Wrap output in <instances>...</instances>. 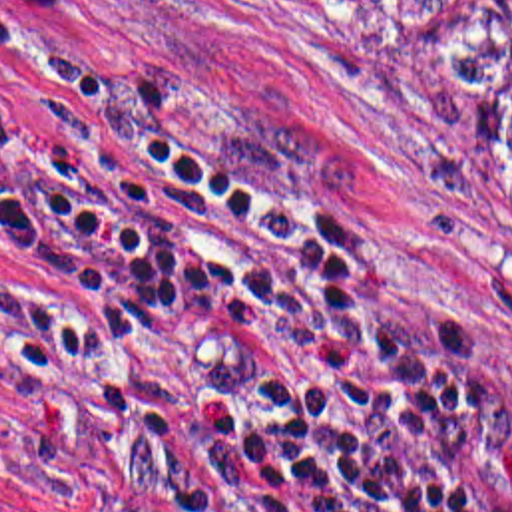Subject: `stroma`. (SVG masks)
Returning <instances> with one entry per match:
<instances>
[{
  "mask_svg": "<svg viewBox=\"0 0 512 512\" xmlns=\"http://www.w3.org/2000/svg\"><path fill=\"white\" fill-rule=\"evenodd\" d=\"M92 69L329 212L385 298L480 353L512 393V0H0ZM30 81L0 61V109ZM40 318L0 250V512H72L2 431Z\"/></svg>",
  "mask_w": 512,
  "mask_h": 512,
  "instance_id": "stroma-1",
  "label": "stroma"
}]
</instances>
